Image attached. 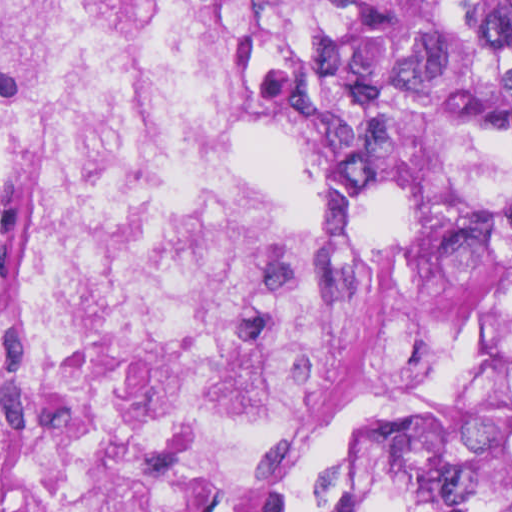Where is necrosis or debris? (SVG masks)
Instances as JSON below:
<instances>
[{
	"label": "necrosis or debris",
	"mask_w": 512,
	"mask_h": 512,
	"mask_svg": "<svg viewBox=\"0 0 512 512\" xmlns=\"http://www.w3.org/2000/svg\"><path fill=\"white\" fill-rule=\"evenodd\" d=\"M214 0H0V512H282L508 280L446 217L267 209Z\"/></svg>",
	"instance_id": "necrosis-or-debris-1"
}]
</instances>
